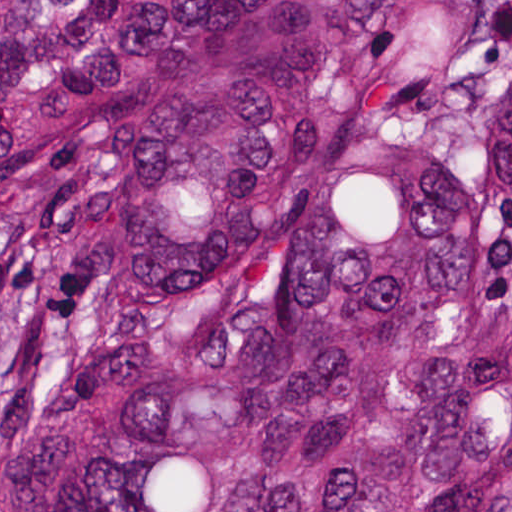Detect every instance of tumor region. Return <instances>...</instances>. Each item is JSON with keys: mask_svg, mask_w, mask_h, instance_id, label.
<instances>
[{"mask_svg": "<svg viewBox=\"0 0 512 512\" xmlns=\"http://www.w3.org/2000/svg\"><path fill=\"white\" fill-rule=\"evenodd\" d=\"M0 512H512V0H0Z\"/></svg>", "mask_w": 512, "mask_h": 512, "instance_id": "tumor-region-1", "label": "tumor region"}]
</instances>
